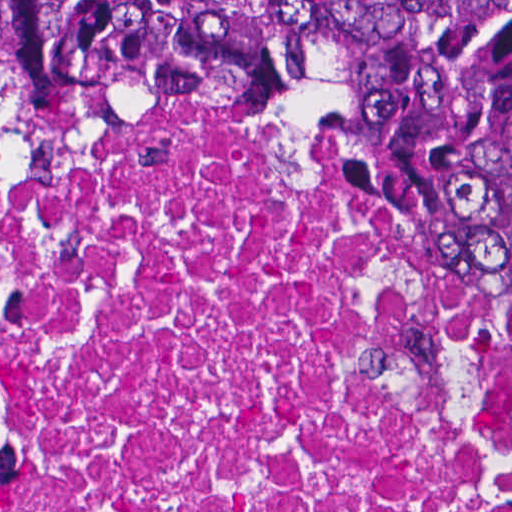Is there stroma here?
<instances>
[{
  "label": "stroma",
  "mask_w": 512,
  "mask_h": 512,
  "mask_svg": "<svg viewBox=\"0 0 512 512\" xmlns=\"http://www.w3.org/2000/svg\"><path fill=\"white\" fill-rule=\"evenodd\" d=\"M0 100L41 130H89L163 161H290L327 169L395 214L411 254L464 293L373 149L357 99L319 78L243 100H201L121 116H26L1 95ZM489 322L512 354V329Z\"/></svg>",
  "instance_id": "stroma-1"
}]
</instances>
